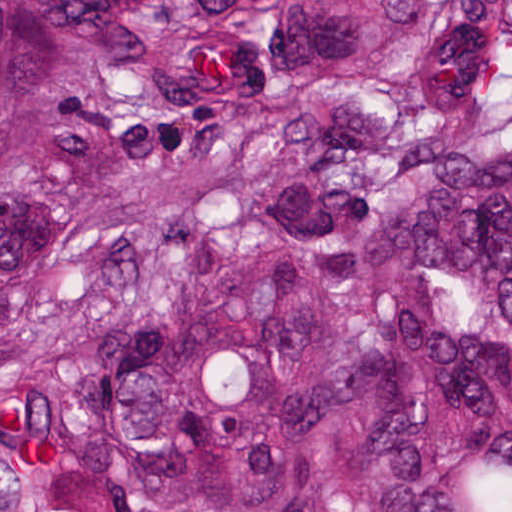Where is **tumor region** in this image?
<instances>
[{
	"label": "tumor region",
	"instance_id": "1",
	"mask_svg": "<svg viewBox=\"0 0 512 512\" xmlns=\"http://www.w3.org/2000/svg\"><path fill=\"white\" fill-rule=\"evenodd\" d=\"M0 512H512V0H0Z\"/></svg>",
	"mask_w": 512,
	"mask_h": 512
}]
</instances>
